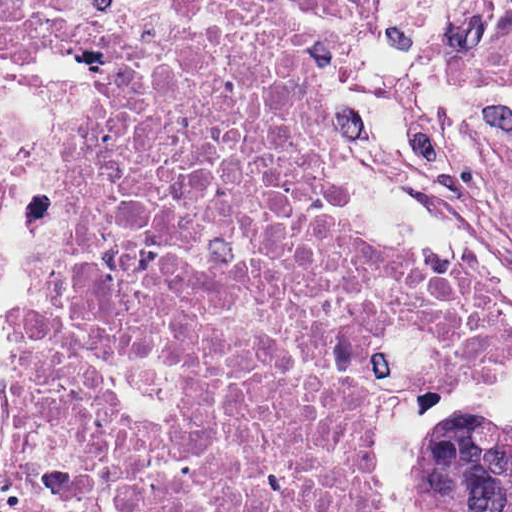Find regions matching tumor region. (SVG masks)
<instances>
[{
    "instance_id": "1",
    "label": "tumor region",
    "mask_w": 512,
    "mask_h": 512,
    "mask_svg": "<svg viewBox=\"0 0 512 512\" xmlns=\"http://www.w3.org/2000/svg\"><path fill=\"white\" fill-rule=\"evenodd\" d=\"M416 462L423 512H512V420L483 413L444 419Z\"/></svg>"
}]
</instances>
